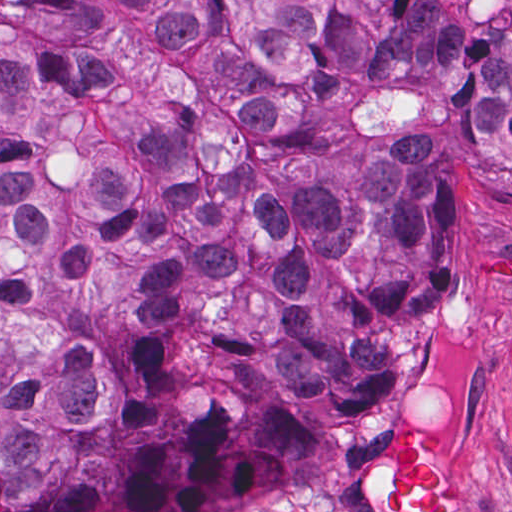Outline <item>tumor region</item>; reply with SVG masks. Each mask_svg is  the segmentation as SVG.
I'll return each mask as SVG.
<instances>
[{
	"mask_svg": "<svg viewBox=\"0 0 512 512\" xmlns=\"http://www.w3.org/2000/svg\"><path fill=\"white\" fill-rule=\"evenodd\" d=\"M512 192V0H0V512L286 500L447 275L441 156ZM370 512H471L402 425Z\"/></svg>",
	"mask_w": 512,
	"mask_h": 512,
	"instance_id": "e687c5a6",
	"label": "tumor region"
}]
</instances>
